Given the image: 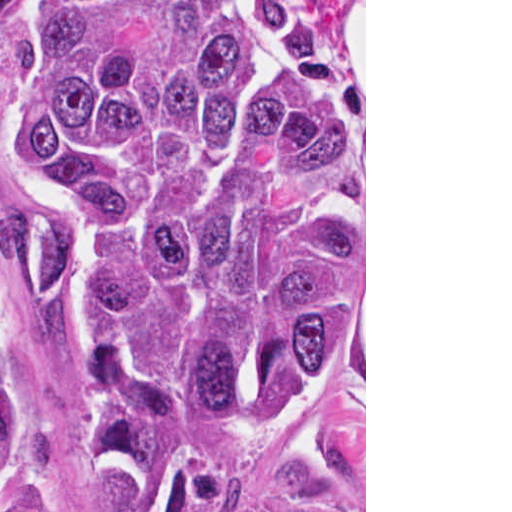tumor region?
<instances>
[{
  "label": "tumor region",
  "mask_w": 512,
  "mask_h": 512,
  "mask_svg": "<svg viewBox=\"0 0 512 512\" xmlns=\"http://www.w3.org/2000/svg\"><path fill=\"white\" fill-rule=\"evenodd\" d=\"M341 0H0L1 131L46 199L0 273L77 388L91 487L212 512L364 334V109ZM0 512H87L26 400L0 290ZM242 512H355L271 486Z\"/></svg>",
  "instance_id": "obj_1"
}]
</instances>
